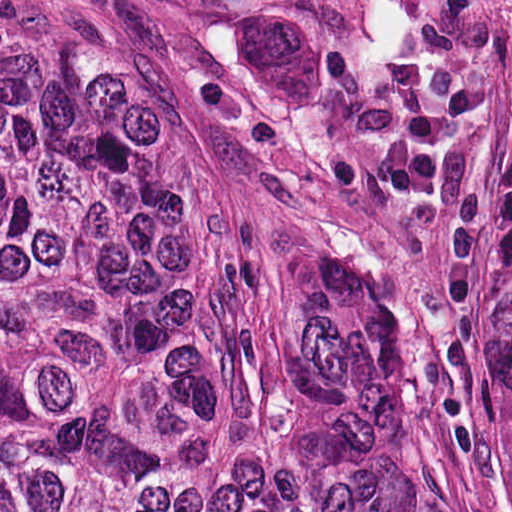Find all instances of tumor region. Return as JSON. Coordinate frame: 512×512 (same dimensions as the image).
Masks as SVG:
<instances>
[{"label": "tumor region", "mask_w": 512, "mask_h": 512, "mask_svg": "<svg viewBox=\"0 0 512 512\" xmlns=\"http://www.w3.org/2000/svg\"><path fill=\"white\" fill-rule=\"evenodd\" d=\"M0 512H310L0 411Z\"/></svg>", "instance_id": "obj_1"}]
</instances>
